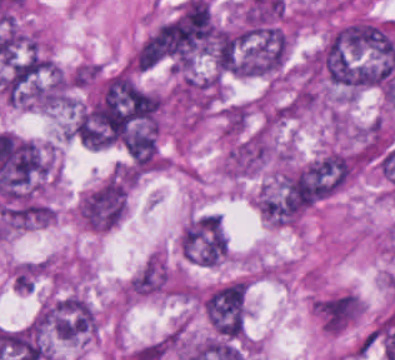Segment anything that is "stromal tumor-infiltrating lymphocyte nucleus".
Wrapping results in <instances>:
<instances>
[{"instance_id": "stromal-tumor-infiltrating-lymphocyte-nucleus-1", "label": "stromal tumor-infiltrating lymphocyte nucleus", "mask_w": 395, "mask_h": 360, "mask_svg": "<svg viewBox=\"0 0 395 360\" xmlns=\"http://www.w3.org/2000/svg\"><path fill=\"white\" fill-rule=\"evenodd\" d=\"M311 309L316 313V300H315V298L311 302Z\"/></svg>"}]
</instances>
